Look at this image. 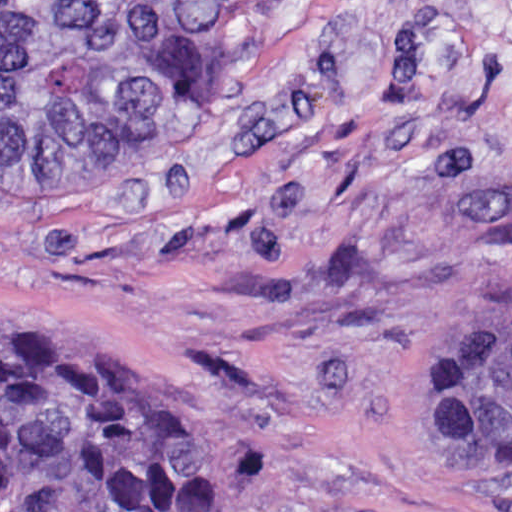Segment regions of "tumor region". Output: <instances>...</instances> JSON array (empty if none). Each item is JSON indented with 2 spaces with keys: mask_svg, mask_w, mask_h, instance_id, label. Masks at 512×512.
Returning <instances> with one entry per match:
<instances>
[{
  "mask_svg": "<svg viewBox=\"0 0 512 512\" xmlns=\"http://www.w3.org/2000/svg\"><path fill=\"white\" fill-rule=\"evenodd\" d=\"M317 1L0 0V163L154 144L249 85ZM150 367L163 380L135 384L0 315V512H223ZM419 392L433 435L512 463V310L444 332Z\"/></svg>",
  "mask_w": 512,
  "mask_h": 512,
  "instance_id": "e687c5a6",
  "label": "tumor region"
}]
</instances>
